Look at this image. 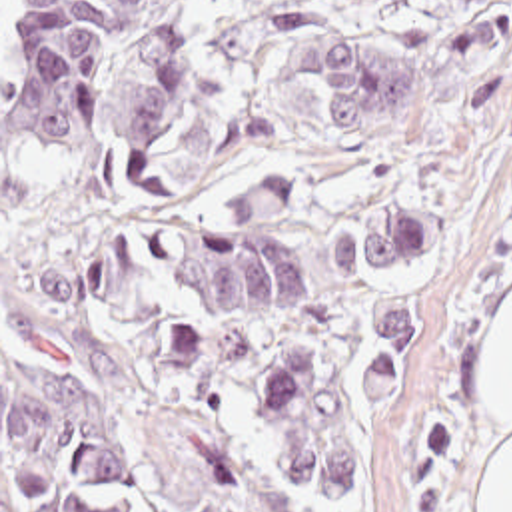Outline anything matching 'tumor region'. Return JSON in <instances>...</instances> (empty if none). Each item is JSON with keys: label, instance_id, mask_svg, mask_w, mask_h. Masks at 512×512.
Segmentation results:
<instances>
[{"label": "tumor region", "instance_id": "1", "mask_svg": "<svg viewBox=\"0 0 512 512\" xmlns=\"http://www.w3.org/2000/svg\"><path fill=\"white\" fill-rule=\"evenodd\" d=\"M441 46L459 70V122H493L509 108L512 0H435ZM307 80L327 132L403 136L417 132L419 72L407 50L337 28L301 38ZM224 330L293 318L313 300L299 262L291 172L266 178L222 208L210 186ZM445 246V224L417 202L369 220H343L329 242L335 264L393 270ZM419 362V306L369 316L351 364L359 394L393 410ZM232 408L254 415L273 461L291 483L339 505L371 511L349 423L321 360L283 352L230 378Z\"/></svg>", "mask_w": 512, "mask_h": 512}]
</instances>
